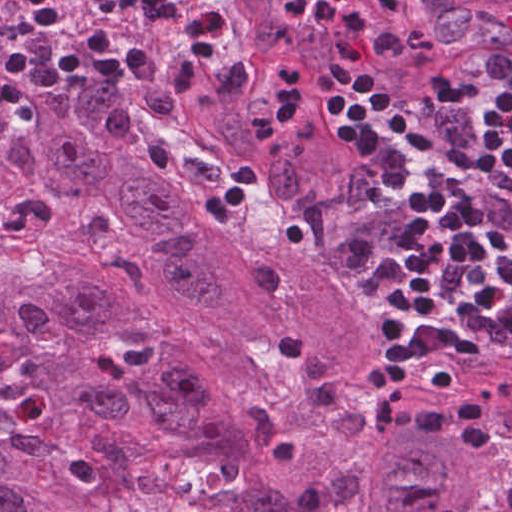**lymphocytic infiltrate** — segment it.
I'll return each mask as SVG.
<instances>
[{"instance_id": "obj_1", "label": "lymphocytic infiltrate", "mask_w": 512, "mask_h": 512, "mask_svg": "<svg viewBox=\"0 0 512 512\" xmlns=\"http://www.w3.org/2000/svg\"><path fill=\"white\" fill-rule=\"evenodd\" d=\"M134 33L88 28L53 44L64 20L61 0H17L21 31L0 56V110L51 115L73 79L126 75L148 83L161 41L146 16L208 53L233 41L235 21L218 0H108ZM276 18L324 31L331 64L318 74L281 65L269 81L267 116L250 124L260 146L300 126L303 94L347 95L325 104L329 138L363 178L338 239L348 276L383 291L378 310L382 368L368 384L373 417L394 438L428 434L492 446L486 407L475 394L444 406L405 403L421 359L464 365L469 349L512 366V55L491 74L411 103L364 95L372 87L357 66L365 16L337 0H282ZM235 168L203 206L215 225L228 222L255 182ZM426 318L412 331L413 307Z\"/></svg>"}]
</instances>
